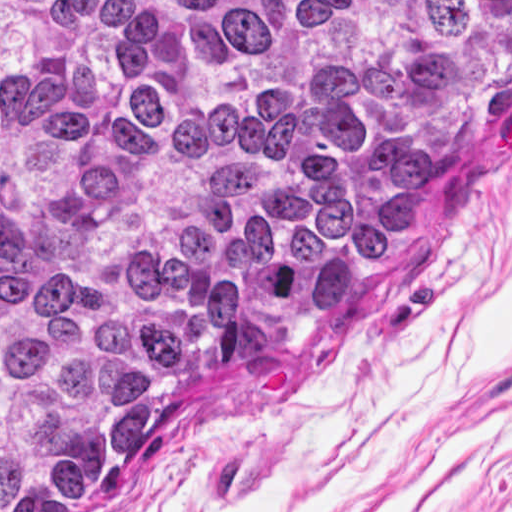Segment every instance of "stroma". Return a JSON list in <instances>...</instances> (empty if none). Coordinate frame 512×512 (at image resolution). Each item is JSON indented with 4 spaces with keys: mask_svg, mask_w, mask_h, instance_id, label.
Listing matches in <instances>:
<instances>
[{
    "mask_svg": "<svg viewBox=\"0 0 512 512\" xmlns=\"http://www.w3.org/2000/svg\"><path fill=\"white\" fill-rule=\"evenodd\" d=\"M53 512H512V122L410 248Z\"/></svg>",
    "mask_w": 512,
    "mask_h": 512,
    "instance_id": "stroma-1",
    "label": "stroma"
}]
</instances>
